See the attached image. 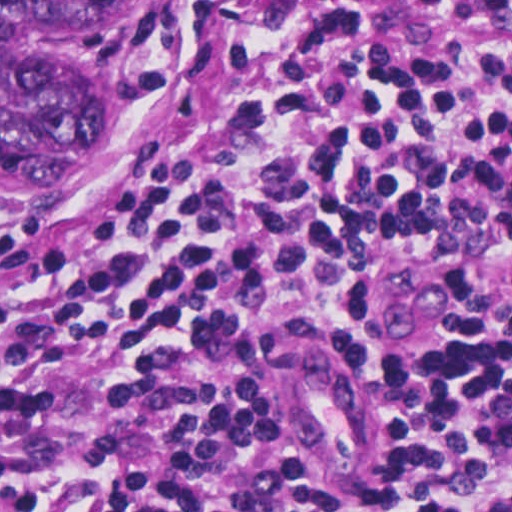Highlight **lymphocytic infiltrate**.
Returning a JSON list of instances; mask_svg holds the SVG:
<instances>
[{"label":"lymphocytic infiltrate","mask_w":512,"mask_h":512,"mask_svg":"<svg viewBox=\"0 0 512 512\" xmlns=\"http://www.w3.org/2000/svg\"><path fill=\"white\" fill-rule=\"evenodd\" d=\"M500 53H396L345 11L188 0L153 155L67 212L0 227V512H512V0ZM414 256L475 302L438 361H369L320 278ZM303 347L364 383L351 469L282 406Z\"/></svg>","instance_id":"1"}]
</instances>
